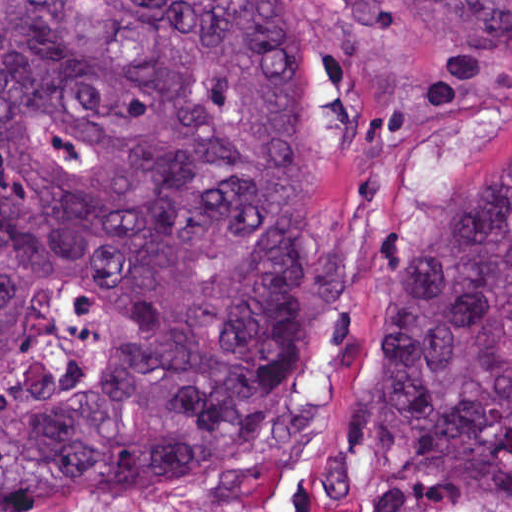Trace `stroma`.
<instances>
[{"label": "stroma", "mask_w": 512, "mask_h": 512, "mask_svg": "<svg viewBox=\"0 0 512 512\" xmlns=\"http://www.w3.org/2000/svg\"><path fill=\"white\" fill-rule=\"evenodd\" d=\"M511 157L512 68L490 64L409 134L374 224L355 218L327 149L345 220V300L307 382L182 489L148 506L73 512H512V494L441 506L392 474L369 436L372 341L393 256L422 219Z\"/></svg>", "instance_id": "obj_1"}]
</instances>
